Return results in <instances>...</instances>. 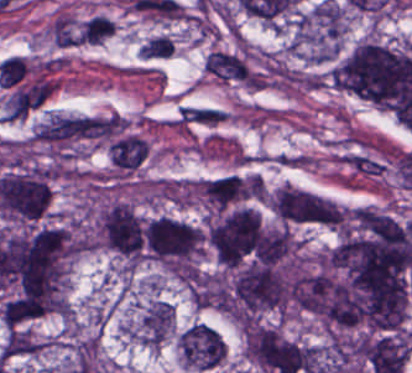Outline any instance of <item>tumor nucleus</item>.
<instances>
[{
  "mask_svg": "<svg viewBox=\"0 0 412 373\" xmlns=\"http://www.w3.org/2000/svg\"><path fill=\"white\" fill-rule=\"evenodd\" d=\"M196 191L216 211L259 198L265 193L262 179L254 174H226L197 181Z\"/></svg>",
  "mask_w": 412,
  "mask_h": 373,
  "instance_id": "obj_7",
  "label": "tumor nucleus"
},
{
  "mask_svg": "<svg viewBox=\"0 0 412 373\" xmlns=\"http://www.w3.org/2000/svg\"><path fill=\"white\" fill-rule=\"evenodd\" d=\"M95 235L99 247L129 264H138L145 249V223L133 206L114 201L98 212Z\"/></svg>",
  "mask_w": 412,
  "mask_h": 373,
  "instance_id": "obj_5",
  "label": "tumor nucleus"
},
{
  "mask_svg": "<svg viewBox=\"0 0 412 373\" xmlns=\"http://www.w3.org/2000/svg\"><path fill=\"white\" fill-rule=\"evenodd\" d=\"M107 152L113 166L122 170H134L149 153V146L135 133L122 132L107 144Z\"/></svg>",
  "mask_w": 412,
  "mask_h": 373,
  "instance_id": "obj_8",
  "label": "tumor nucleus"
},
{
  "mask_svg": "<svg viewBox=\"0 0 412 373\" xmlns=\"http://www.w3.org/2000/svg\"><path fill=\"white\" fill-rule=\"evenodd\" d=\"M205 239L223 266L248 268L262 258V218L252 207L217 212L205 226Z\"/></svg>",
  "mask_w": 412,
  "mask_h": 373,
  "instance_id": "obj_2",
  "label": "tumor nucleus"
},
{
  "mask_svg": "<svg viewBox=\"0 0 412 373\" xmlns=\"http://www.w3.org/2000/svg\"><path fill=\"white\" fill-rule=\"evenodd\" d=\"M275 216L287 224L339 225L340 208L324 196L283 185L269 200Z\"/></svg>",
  "mask_w": 412,
  "mask_h": 373,
  "instance_id": "obj_6",
  "label": "tumor nucleus"
},
{
  "mask_svg": "<svg viewBox=\"0 0 412 373\" xmlns=\"http://www.w3.org/2000/svg\"><path fill=\"white\" fill-rule=\"evenodd\" d=\"M330 83L382 108L412 110V52L364 40L329 72Z\"/></svg>",
  "mask_w": 412,
  "mask_h": 373,
  "instance_id": "obj_1",
  "label": "tumor nucleus"
},
{
  "mask_svg": "<svg viewBox=\"0 0 412 373\" xmlns=\"http://www.w3.org/2000/svg\"><path fill=\"white\" fill-rule=\"evenodd\" d=\"M346 11L331 1L320 2L297 15L289 45L313 61L337 55L345 34Z\"/></svg>",
  "mask_w": 412,
  "mask_h": 373,
  "instance_id": "obj_4",
  "label": "tumor nucleus"
},
{
  "mask_svg": "<svg viewBox=\"0 0 412 373\" xmlns=\"http://www.w3.org/2000/svg\"><path fill=\"white\" fill-rule=\"evenodd\" d=\"M202 239V228L170 216L147 218L143 234L147 258L171 270H193Z\"/></svg>",
  "mask_w": 412,
  "mask_h": 373,
  "instance_id": "obj_3",
  "label": "tumor nucleus"
}]
</instances>
